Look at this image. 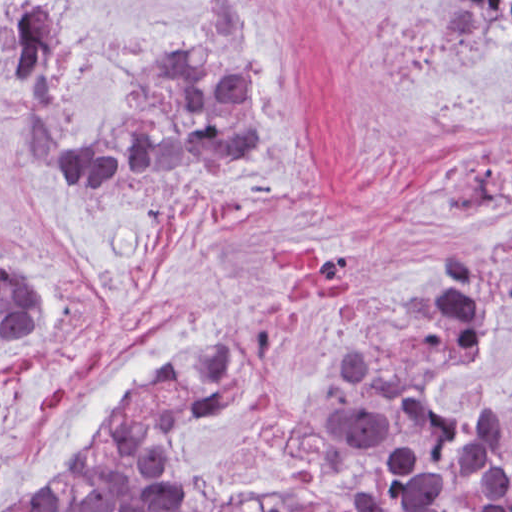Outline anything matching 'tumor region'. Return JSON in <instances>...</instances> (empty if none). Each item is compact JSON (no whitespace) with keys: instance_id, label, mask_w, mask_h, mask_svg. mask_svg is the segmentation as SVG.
Returning a JSON list of instances; mask_svg holds the SVG:
<instances>
[{"instance_id":"tumor-region-1","label":"tumor region","mask_w":512,"mask_h":512,"mask_svg":"<svg viewBox=\"0 0 512 512\" xmlns=\"http://www.w3.org/2000/svg\"><path fill=\"white\" fill-rule=\"evenodd\" d=\"M432 26L435 37L475 48L512 33V1H434ZM68 57L54 1H9L2 80L21 115L17 159L33 178L107 187L134 166L179 160L236 174L260 158L264 99L249 1H221L207 32L157 62L111 119L77 134L63 91ZM511 306L512 223L416 281L365 324L295 470L267 488L316 480L332 432L357 411L468 422L445 417L441 397L495 311ZM47 313L44 286L0 252V346ZM246 329L187 334L177 353L114 408L74 468L6 512H212L267 489L210 487L203 468L222 418V380ZM473 422L494 434L512 482V402Z\"/></svg>"}]
</instances>
